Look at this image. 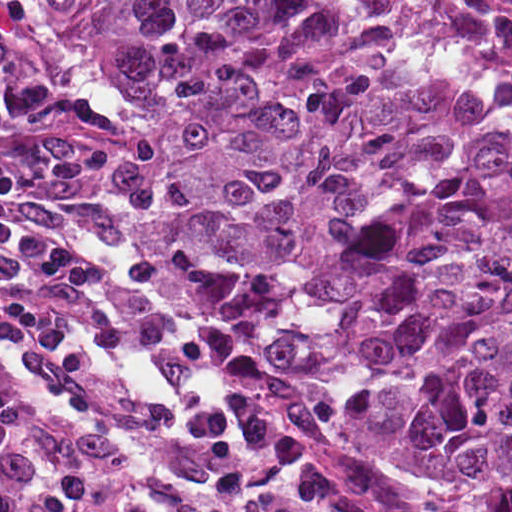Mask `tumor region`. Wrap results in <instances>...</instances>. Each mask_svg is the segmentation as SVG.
I'll list each match as a JSON object with an SVG mask.
<instances>
[{"mask_svg": "<svg viewBox=\"0 0 512 512\" xmlns=\"http://www.w3.org/2000/svg\"><path fill=\"white\" fill-rule=\"evenodd\" d=\"M161 143L169 288L301 420L512 512V111L343 1H31Z\"/></svg>", "mask_w": 512, "mask_h": 512, "instance_id": "e687c5a6", "label": "tumor region"}]
</instances>
